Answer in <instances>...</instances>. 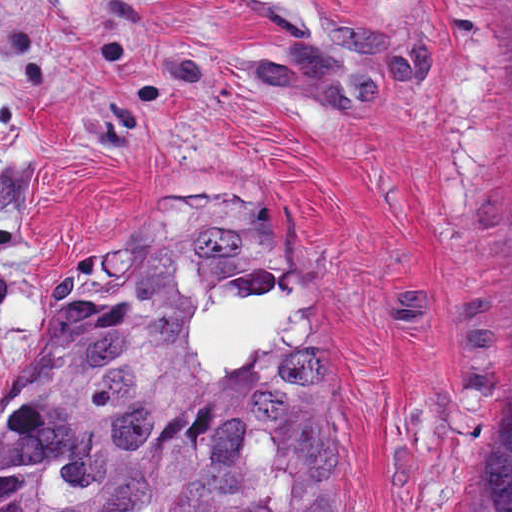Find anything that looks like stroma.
Here are the masks:
<instances>
[{
    "label": "stroma",
    "instance_id": "1",
    "mask_svg": "<svg viewBox=\"0 0 512 512\" xmlns=\"http://www.w3.org/2000/svg\"><path fill=\"white\" fill-rule=\"evenodd\" d=\"M134 228L275 235L357 512H464L512 260V0H0V403Z\"/></svg>",
    "mask_w": 512,
    "mask_h": 512
}]
</instances>
